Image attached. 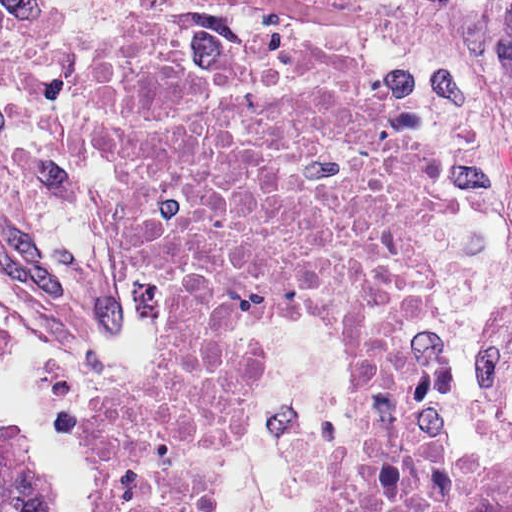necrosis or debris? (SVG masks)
I'll list each match as a JSON object with an SVG mask.
<instances>
[{
    "label": "necrosis or debris",
    "instance_id": "4bbe7bcc",
    "mask_svg": "<svg viewBox=\"0 0 512 512\" xmlns=\"http://www.w3.org/2000/svg\"><path fill=\"white\" fill-rule=\"evenodd\" d=\"M80 106L112 257L155 326L151 368L92 414L108 512H224L259 342L240 334L269 313L353 350L345 430L318 410L287 430L306 512H512L508 458L448 431L440 175L397 64L158 9L98 46ZM5 334L0 310V353Z\"/></svg>",
    "mask_w": 512,
    "mask_h": 512
}]
</instances>
